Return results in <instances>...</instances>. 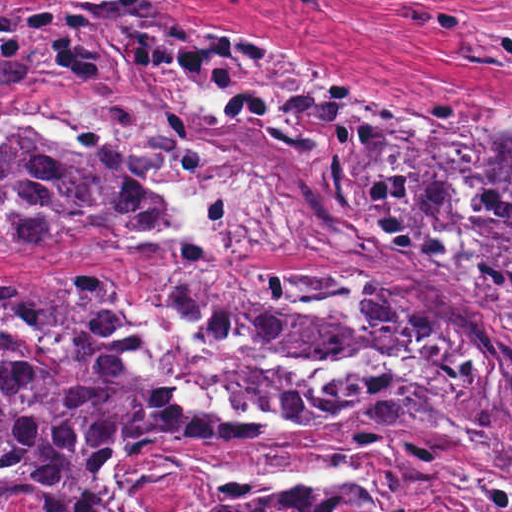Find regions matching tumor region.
Here are the masks:
<instances>
[{
  "label": "tumor region",
  "instance_id": "e687c5a6",
  "mask_svg": "<svg viewBox=\"0 0 512 512\" xmlns=\"http://www.w3.org/2000/svg\"><path fill=\"white\" fill-rule=\"evenodd\" d=\"M244 1V0H241ZM327 12L331 0H302ZM388 19L459 38L453 64L512 76V21L456 0H369ZM512 14V0H467ZM1 76L142 91L239 163L366 228L329 232L343 267L277 271H1V512H108L134 461L268 434L408 423L512 470V125L490 149L477 226L456 219L474 144L470 123L433 105L430 122L377 105L325 72L214 27L165 0L1 5ZM310 221L251 198L205 156L137 119L110 135H1V250L130 239L187 250L277 251ZM144 311L214 345L186 381L216 383L247 357L319 363L386 358L384 372L319 389L275 371L241 377L244 425L142 379L122 333ZM372 493L297 490L208 512H384Z\"/></svg>",
  "mask_w": 512,
  "mask_h": 512
}]
</instances>
